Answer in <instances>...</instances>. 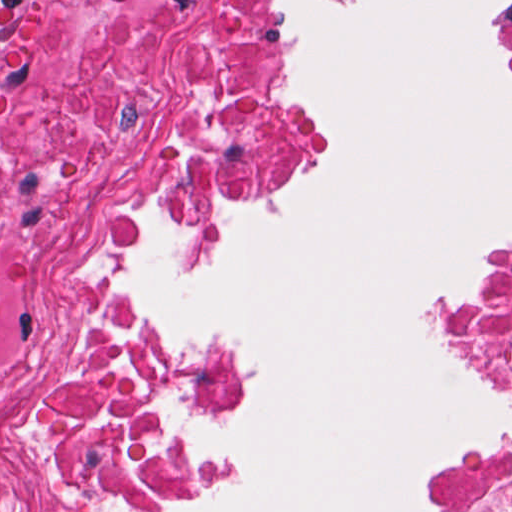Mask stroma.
Masks as SVG:
<instances>
[{
	"label": "stroma",
	"instance_id": "1",
	"mask_svg": "<svg viewBox=\"0 0 512 512\" xmlns=\"http://www.w3.org/2000/svg\"><path fill=\"white\" fill-rule=\"evenodd\" d=\"M66 2L22 0L14 21V80L7 95V116L0 122L49 102ZM264 4L272 44L304 106L299 148L253 191L214 208L159 212V249L174 264L233 237L221 216L282 200L301 189L320 150V121L307 86L293 67L289 42L277 27L289 0H264ZM492 72L512 105V9L496 12ZM453 91L493 121L507 115ZM157 233L158 212L150 213L143 245ZM510 246L512 221L488 253L468 257V276L456 296L436 304L433 328L443 347L462 361L486 390L512 404V375L499 355L481 346L477 329V304L494 256ZM189 338L226 377L194 422H234L253 411L261 392L253 369V347L234 336L215 344ZM181 436L200 474L204 506H217L225 488L217 468V446L190 426ZM482 483H512V451H435L424 469L420 512H452L465 494Z\"/></svg>",
	"mask_w": 512,
	"mask_h": 512
}]
</instances>
